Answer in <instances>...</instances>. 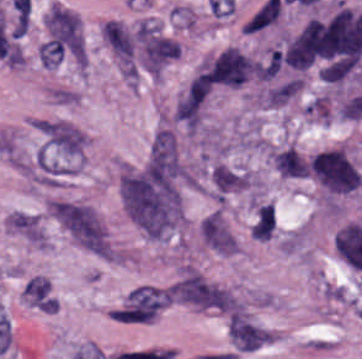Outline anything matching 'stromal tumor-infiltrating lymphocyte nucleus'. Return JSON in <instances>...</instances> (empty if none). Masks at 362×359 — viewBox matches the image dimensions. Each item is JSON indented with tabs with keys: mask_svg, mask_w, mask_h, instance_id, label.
Segmentation results:
<instances>
[{
	"mask_svg": "<svg viewBox=\"0 0 362 359\" xmlns=\"http://www.w3.org/2000/svg\"><path fill=\"white\" fill-rule=\"evenodd\" d=\"M22 298L41 311H54V296L47 278L32 274L22 288Z\"/></svg>",
	"mask_w": 362,
	"mask_h": 359,
	"instance_id": "obj_1",
	"label": "stromal tumor-infiltrating lymphocyte nucleus"
}]
</instances>
